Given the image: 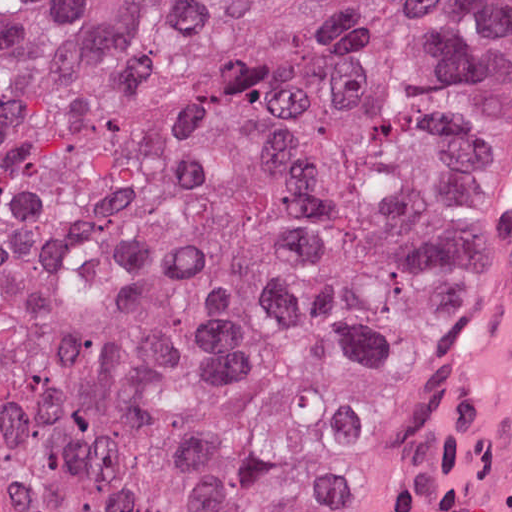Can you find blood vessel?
Here are the masks:
<instances>
[{
    "mask_svg": "<svg viewBox=\"0 0 512 512\" xmlns=\"http://www.w3.org/2000/svg\"><path fill=\"white\" fill-rule=\"evenodd\" d=\"M377 512H512V301L476 379L418 443Z\"/></svg>",
    "mask_w": 512,
    "mask_h": 512,
    "instance_id": "obj_1",
    "label": "blood vessel"
}]
</instances>
